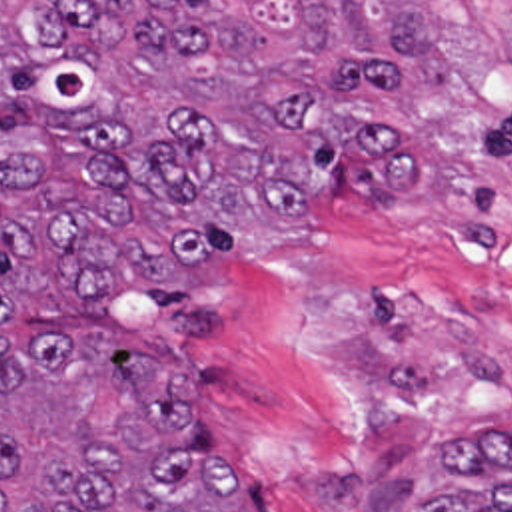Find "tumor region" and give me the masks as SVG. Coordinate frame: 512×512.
Instances as JSON below:
<instances>
[{"label": "tumor region", "mask_w": 512, "mask_h": 512, "mask_svg": "<svg viewBox=\"0 0 512 512\" xmlns=\"http://www.w3.org/2000/svg\"><path fill=\"white\" fill-rule=\"evenodd\" d=\"M454 84L440 0H0V512H276L176 350L240 252L328 234L338 172L434 182L376 114ZM464 438L412 512H512V438Z\"/></svg>", "instance_id": "e687c5a6"}]
</instances>
